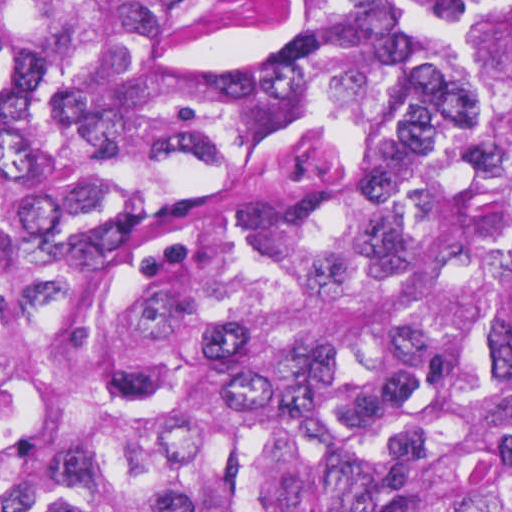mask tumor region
Here are the masks:
<instances>
[{
	"instance_id": "e687c5a6",
	"label": "tumor region",
	"mask_w": 512,
	"mask_h": 512,
	"mask_svg": "<svg viewBox=\"0 0 512 512\" xmlns=\"http://www.w3.org/2000/svg\"><path fill=\"white\" fill-rule=\"evenodd\" d=\"M0 512H512V0H0Z\"/></svg>"
}]
</instances>
